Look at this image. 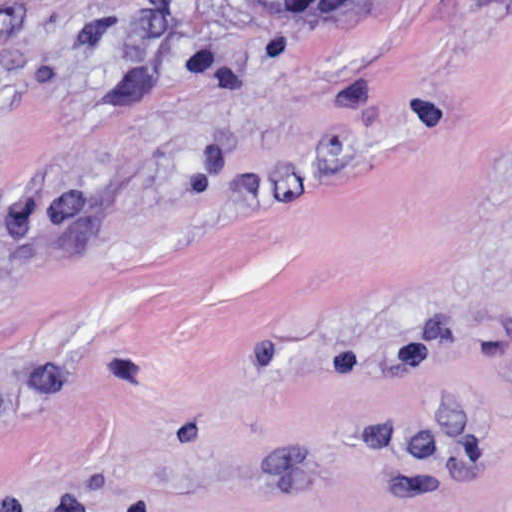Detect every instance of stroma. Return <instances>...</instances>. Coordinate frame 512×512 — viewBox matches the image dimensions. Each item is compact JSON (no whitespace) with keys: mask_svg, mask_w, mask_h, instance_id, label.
I'll list each match as a JSON object with an SVG mask.
<instances>
[{"mask_svg":"<svg viewBox=\"0 0 512 512\" xmlns=\"http://www.w3.org/2000/svg\"><path fill=\"white\" fill-rule=\"evenodd\" d=\"M0 512H512V0H0Z\"/></svg>","mask_w":512,"mask_h":512,"instance_id":"stroma-1","label":"stroma"}]
</instances>
